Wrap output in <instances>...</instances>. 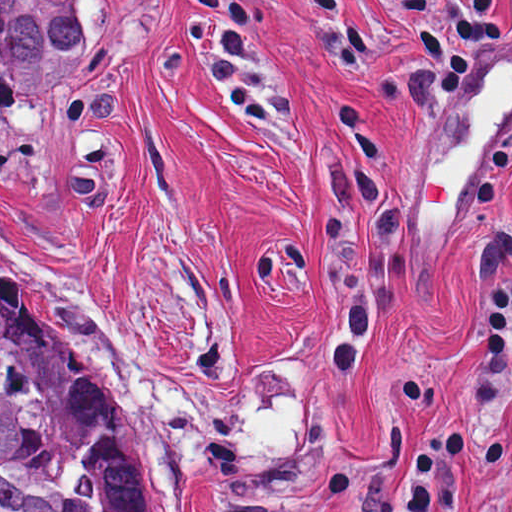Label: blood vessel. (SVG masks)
Instances as JSON below:
<instances>
[{
  "mask_svg": "<svg viewBox=\"0 0 512 512\" xmlns=\"http://www.w3.org/2000/svg\"><path fill=\"white\" fill-rule=\"evenodd\" d=\"M490 83L482 113L471 137L442 164L428 166L424 180V213L458 209L461 186L475 173L486 143L512 103V65L495 59L484 90Z\"/></svg>",
  "mask_w": 512,
  "mask_h": 512,
  "instance_id": "8fb6f2fc",
  "label": "blood vessel"
}]
</instances>
